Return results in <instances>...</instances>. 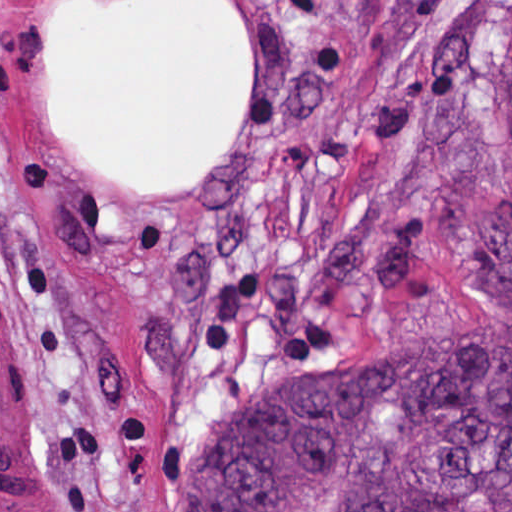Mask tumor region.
<instances>
[{"instance_id":"1","label":"tumor region","mask_w":512,"mask_h":512,"mask_svg":"<svg viewBox=\"0 0 512 512\" xmlns=\"http://www.w3.org/2000/svg\"><path fill=\"white\" fill-rule=\"evenodd\" d=\"M480 98L512 143V0ZM511 322L276 374L199 438L158 512H512V331L492 325Z\"/></svg>"}]
</instances>
